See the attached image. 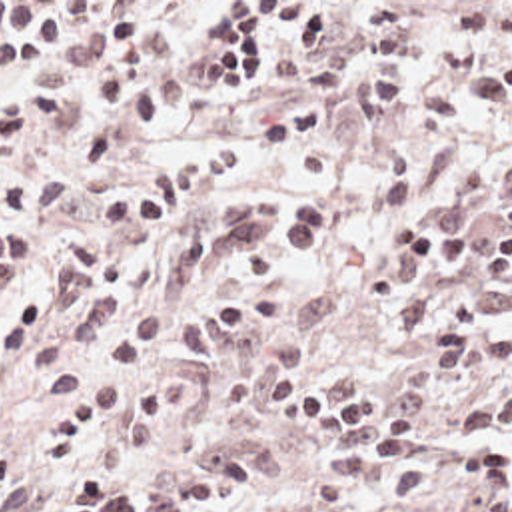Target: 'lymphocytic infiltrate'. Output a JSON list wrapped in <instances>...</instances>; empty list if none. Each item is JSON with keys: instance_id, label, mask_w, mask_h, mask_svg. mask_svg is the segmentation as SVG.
Returning <instances> with one entry per match:
<instances>
[{"instance_id": "obj_1", "label": "lymphocytic infiltrate", "mask_w": 512, "mask_h": 512, "mask_svg": "<svg viewBox=\"0 0 512 512\" xmlns=\"http://www.w3.org/2000/svg\"><path fill=\"white\" fill-rule=\"evenodd\" d=\"M188 2H101L75 60L51 62L85 20V2H0V166L57 112L67 78L91 84V130L67 160L13 180L0 192V292L41 264L47 232L83 180L123 156L139 136L181 116L184 90L171 68V30ZM370 24L362 60L368 118L396 116L414 70L476 56L496 40L500 56L462 84L472 120L512 112V2H462L442 46L422 40L412 2H360ZM296 30L298 58L324 52L318 2H222L202 44L214 62L208 88H250L262 18ZM344 96V60L316 66L298 94L262 118L268 156H294L300 178H328L324 124ZM232 148L181 154L113 190L97 208L103 242L73 236L53 258L47 288L23 292L0 312V361L25 351V367L61 401L41 433V453L69 467L55 512H216L260 481L242 445L208 451L151 487H133L99 463L143 457L177 427L190 387L141 365L177 325L188 359L230 357L222 401L236 413L266 409L326 453V483L348 501L386 485L396 507L452 487L506 501L512 495V218L488 234L446 224L390 220L382 242L400 256L364 278L368 304L400 310V335L420 347L386 395L358 373L306 359L334 317L330 288L282 298L314 278L308 258L330 224L310 192L218 196L236 176ZM456 262L438 256L450 250ZM39 491L23 457L0 447V512H29Z\"/></svg>"}]
</instances>
